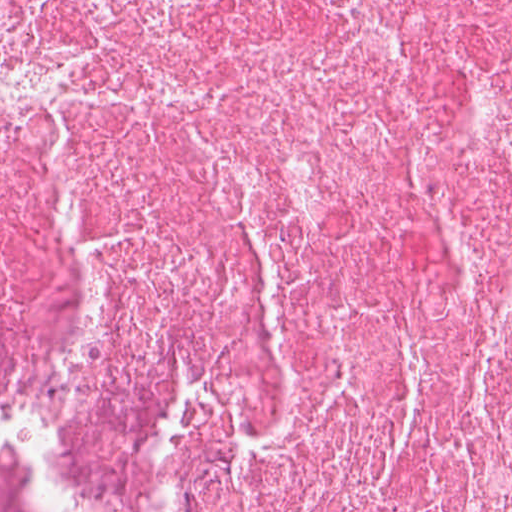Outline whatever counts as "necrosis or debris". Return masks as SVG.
Returning a JSON list of instances; mask_svg holds the SVG:
<instances>
[{"instance_id": "1", "label": "necrosis or debris", "mask_w": 512, "mask_h": 512, "mask_svg": "<svg viewBox=\"0 0 512 512\" xmlns=\"http://www.w3.org/2000/svg\"><path fill=\"white\" fill-rule=\"evenodd\" d=\"M0 512H512V0H0Z\"/></svg>"}]
</instances>
